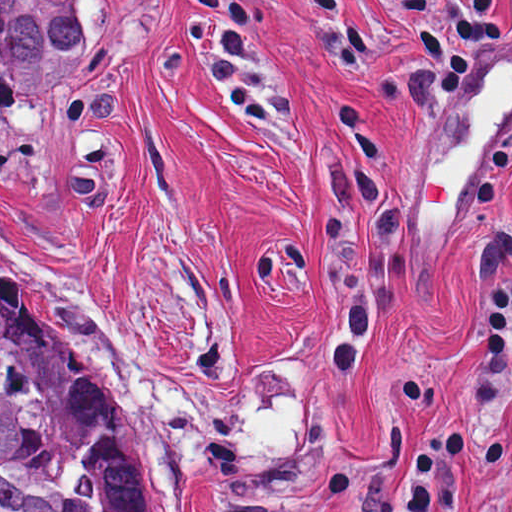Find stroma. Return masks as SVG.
Segmentation results:
<instances>
[{"label": "stroma", "mask_w": 512, "mask_h": 512, "mask_svg": "<svg viewBox=\"0 0 512 512\" xmlns=\"http://www.w3.org/2000/svg\"><path fill=\"white\" fill-rule=\"evenodd\" d=\"M79 1V64L0 103V265L85 356L146 512H499L484 321L512 103L460 189L512 0Z\"/></svg>", "instance_id": "1"}]
</instances>
